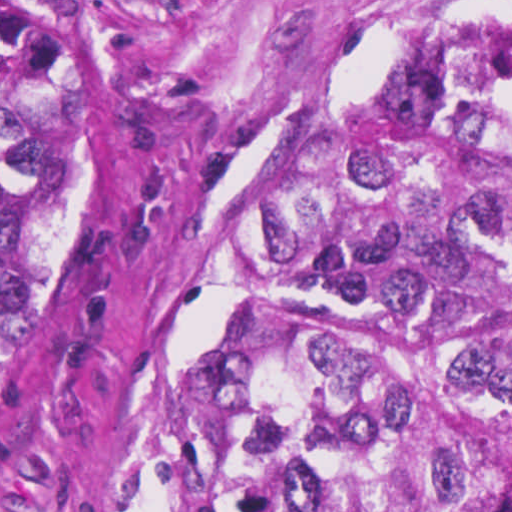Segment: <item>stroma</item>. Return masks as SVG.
I'll return each instance as SVG.
<instances>
[{
	"mask_svg": "<svg viewBox=\"0 0 512 512\" xmlns=\"http://www.w3.org/2000/svg\"><path fill=\"white\" fill-rule=\"evenodd\" d=\"M0 1L50 28L58 119L89 124L87 249L0 410V512H145L150 380L250 304L323 301L264 269L293 161L423 29L512 0ZM444 346L453 512H512V404Z\"/></svg>",
	"mask_w": 512,
	"mask_h": 512,
	"instance_id": "1",
	"label": "stroma"
}]
</instances>
